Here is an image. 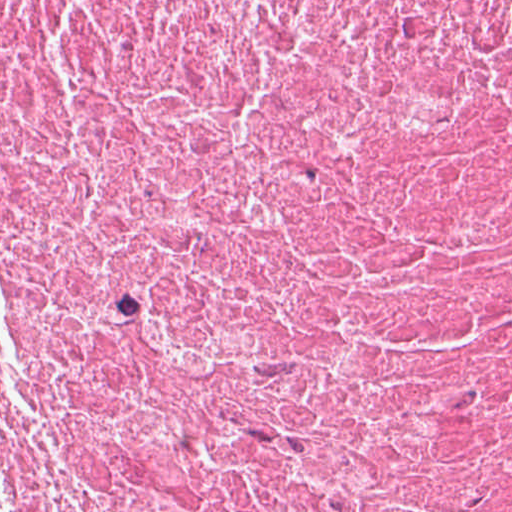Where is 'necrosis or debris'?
Returning <instances> with one entry per match:
<instances>
[{"mask_svg":"<svg viewBox=\"0 0 512 512\" xmlns=\"http://www.w3.org/2000/svg\"><path fill=\"white\" fill-rule=\"evenodd\" d=\"M0 512H512V0H0Z\"/></svg>","mask_w":512,"mask_h":512,"instance_id":"necrosis-or-debris-1","label":"necrosis or debris"}]
</instances>
